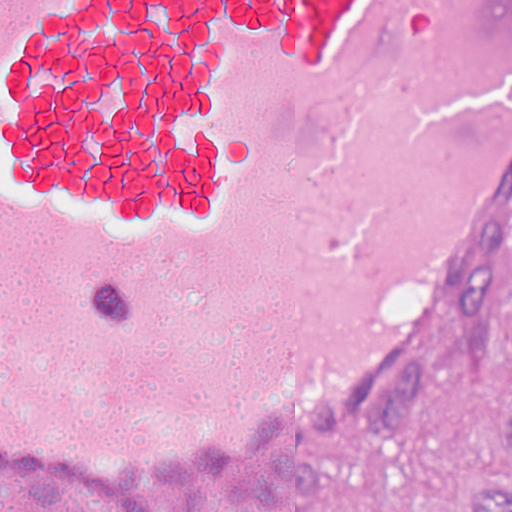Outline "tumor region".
<instances>
[{
  "mask_svg": "<svg viewBox=\"0 0 512 512\" xmlns=\"http://www.w3.org/2000/svg\"><path fill=\"white\" fill-rule=\"evenodd\" d=\"M505 424L512 436V402ZM27 512H102L92 505H40ZM477 512H512V469L485 470L477 488Z\"/></svg>",
  "mask_w": 512,
  "mask_h": 512,
  "instance_id": "e687c5a6",
  "label": "tumor region"
}]
</instances>
